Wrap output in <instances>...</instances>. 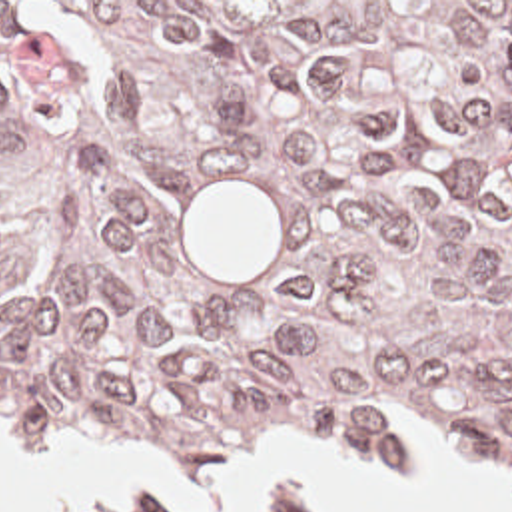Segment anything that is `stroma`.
<instances>
[{"label": "stroma", "mask_w": 512, "mask_h": 512, "mask_svg": "<svg viewBox=\"0 0 512 512\" xmlns=\"http://www.w3.org/2000/svg\"><path fill=\"white\" fill-rule=\"evenodd\" d=\"M0 2H512V0H0ZM380 407L418 409L444 437L480 451H512V423H480L438 399H370L348 403L334 411L316 413L297 419L261 423L219 433L153 431L139 423H57L65 435L81 437L93 443H139L137 431L147 443L143 451L157 453L179 449L193 455L201 469L215 465L231 453L247 447L259 433L275 429H338L344 439L364 457L384 465H404L402 451L370 429L368 415ZM0 427L9 445L21 453L37 451L55 441L57 431L47 423H21L0 417ZM99 512H205L189 511L181 505H141L133 499L117 501ZM287 512H299L289 491Z\"/></svg>", "instance_id": "obj_1"}]
</instances>
